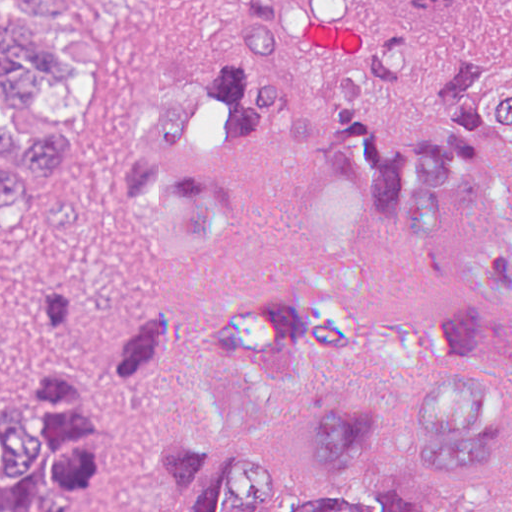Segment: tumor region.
<instances>
[{
    "label": "tumor region",
    "instance_id": "tumor-region-1",
    "mask_svg": "<svg viewBox=\"0 0 512 512\" xmlns=\"http://www.w3.org/2000/svg\"><path fill=\"white\" fill-rule=\"evenodd\" d=\"M50 51L0 20V205L56 176L67 143L14 113L54 90ZM291 146L311 178L313 264L237 297L198 369L204 419L168 441L129 512H437L355 480L397 416L435 470L512 460V12L491 0H220L211 66L132 114L127 204L154 269L181 279L227 237L233 179ZM181 331L154 312L101 363L77 304L30 278L25 367L0 403V512H93L118 398ZM454 512H512L492 495Z\"/></svg>",
    "mask_w": 512,
    "mask_h": 512
}]
</instances>
